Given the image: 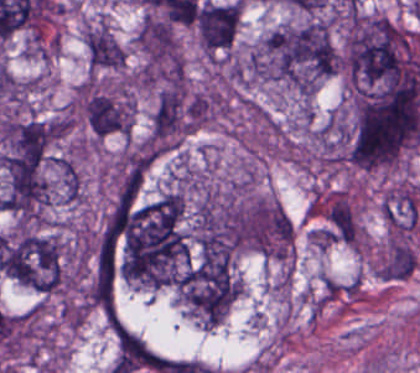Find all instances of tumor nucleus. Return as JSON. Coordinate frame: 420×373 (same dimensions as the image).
I'll return each instance as SVG.
<instances>
[{"label": "tumor nucleus", "mask_w": 420, "mask_h": 373, "mask_svg": "<svg viewBox=\"0 0 420 373\" xmlns=\"http://www.w3.org/2000/svg\"><path fill=\"white\" fill-rule=\"evenodd\" d=\"M420 141V90L367 87L358 94L349 153L365 167L389 165Z\"/></svg>", "instance_id": "2f306a5c"}, {"label": "tumor nucleus", "mask_w": 420, "mask_h": 373, "mask_svg": "<svg viewBox=\"0 0 420 373\" xmlns=\"http://www.w3.org/2000/svg\"><path fill=\"white\" fill-rule=\"evenodd\" d=\"M241 17L240 0L207 1L198 5L195 15L199 41L207 54L232 45Z\"/></svg>", "instance_id": "3d1891a8"}, {"label": "tumor nucleus", "mask_w": 420, "mask_h": 373, "mask_svg": "<svg viewBox=\"0 0 420 373\" xmlns=\"http://www.w3.org/2000/svg\"><path fill=\"white\" fill-rule=\"evenodd\" d=\"M216 99L213 94L195 93L188 98L185 125L196 129L212 115Z\"/></svg>", "instance_id": "268c6acd"}, {"label": "tumor nucleus", "mask_w": 420, "mask_h": 373, "mask_svg": "<svg viewBox=\"0 0 420 373\" xmlns=\"http://www.w3.org/2000/svg\"><path fill=\"white\" fill-rule=\"evenodd\" d=\"M9 276L39 292L62 285L60 243L51 234L19 233L6 240Z\"/></svg>", "instance_id": "2cbd58db"}, {"label": "tumor nucleus", "mask_w": 420, "mask_h": 373, "mask_svg": "<svg viewBox=\"0 0 420 373\" xmlns=\"http://www.w3.org/2000/svg\"><path fill=\"white\" fill-rule=\"evenodd\" d=\"M337 65L328 24L316 19L275 28L262 41V75L296 86H315Z\"/></svg>", "instance_id": "8643909e"}, {"label": "tumor nucleus", "mask_w": 420, "mask_h": 373, "mask_svg": "<svg viewBox=\"0 0 420 373\" xmlns=\"http://www.w3.org/2000/svg\"><path fill=\"white\" fill-rule=\"evenodd\" d=\"M51 134V123L33 116H7L2 139L13 156L39 162Z\"/></svg>", "instance_id": "2083b535"}, {"label": "tumor nucleus", "mask_w": 420, "mask_h": 373, "mask_svg": "<svg viewBox=\"0 0 420 373\" xmlns=\"http://www.w3.org/2000/svg\"><path fill=\"white\" fill-rule=\"evenodd\" d=\"M324 232L331 240L356 245L358 220L344 192L338 191L329 201Z\"/></svg>", "instance_id": "3e47fb67"}, {"label": "tumor nucleus", "mask_w": 420, "mask_h": 373, "mask_svg": "<svg viewBox=\"0 0 420 373\" xmlns=\"http://www.w3.org/2000/svg\"><path fill=\"white\" fill-rule=\"evenodd\" d=\"M137 44L148 63H174L179 59L174 28L167 20L145 15L138 27Z\"/></svg>", "instance_id": "feef74b5"}, {"label": "tumor nucleus", "mask_w": 420, "mask_h": 373, "mask_svg": "<svg viewBox=\"0 0 420 373\" xmlns=\"http://www.w3.org/2000/svg\"><path fill=\"white\" fill-rule=\"evenodd\" d=\"M85 45L94 67L120 68L124 64L126 52L100 23L86 28Z\"/></svg>", "instance_id": "f7901128"}, {"label": "tumor nucleus", "mask_w": 420, "mask_h": 373, "mask_svg": "<svg viewBox=\"0 0 420 373\" xmlns=\"http://www.w3.org/2000/svg\"><path fill=\"white\" fill-rule=\"evenodd\" d=\"M188 93L182 86L159 93L151 122V139L161 149L174 146L185 127Z\"/></svg>", "instance_id": "8087334f"}, {"label": "tumor nucleus", "mask_w": 420, "mask_h": 373, "mask_svg": "<svg viewBox=\"0 0 420 373\" xmlns=\"http://www.w3.org/2000/svg\"><path fill=\"white\" fill-rule=\"evenodd\" d=\"M240 287L230 255L203 259L177 279V290L191 310L214 325L232 305Z\"/></svg>", "instance_id": "5ab6c2c4"}, {"label": "tumor nucleus", "mask_w": 420, "mask_h": 373, "mask_svg": "<svg viewBox=\"0 0 420 373\" xmlns=\"http://www.w3.org/2000/svg\"><path fill=\"white\" fill-rule=\"evenodd\" d=\"M86 119L96 136L127 132L131 109L123 99L103 92H90L84 101Z\"/></svg>", "instance_id": "c2bd9aea"}]
</instances>
